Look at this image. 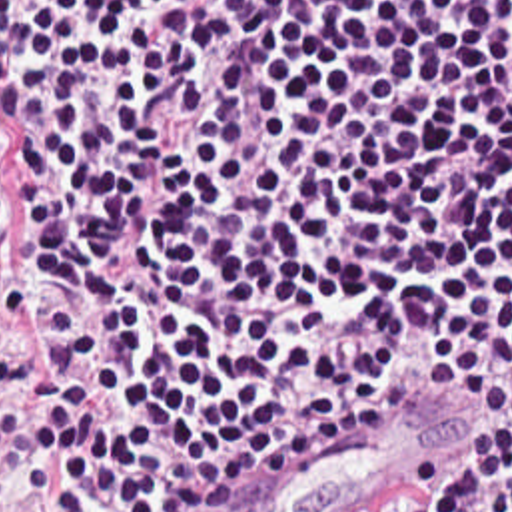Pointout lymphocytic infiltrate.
<instances>
[{"label": "lymphocytic infiltrate", "mask_w": 512, "mask_h": 512, "mask_svg": "<svg viewBox=\"0 0 512 512\" xmlns=\"http://www.w3.org/2000/svg\"><path fill=\"white\" fill-rule=\"evenodd\" d=\"M426 390L460 438L336 512H512V0H0V494Z\"/></svg>", "instance_id": "1"}]
</instances>
